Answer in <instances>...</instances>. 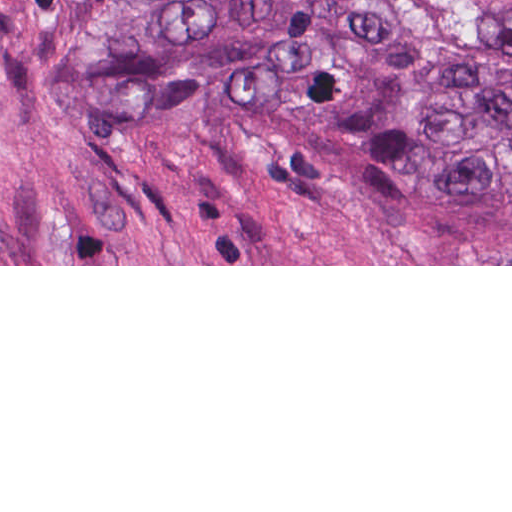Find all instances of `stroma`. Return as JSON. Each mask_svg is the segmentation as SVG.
<instances>
[{
  "label": "stroma",
  "instance_id": "1",
  "mask_svg": "<svg viewBox=\"0 0 512 512\" xmlns=\"http://www.w3.org/2000/svg\"><path fill=\"white\" fill-rule=\"evenodd\" d=\"M447 42L512 63L406 0ZM92 0H0V266H512V231L392 190L239 89L158 119L50 86Z\"/></svg>",
  "mask_w": 512,
  "mask_h": 512
}]
</instances>
